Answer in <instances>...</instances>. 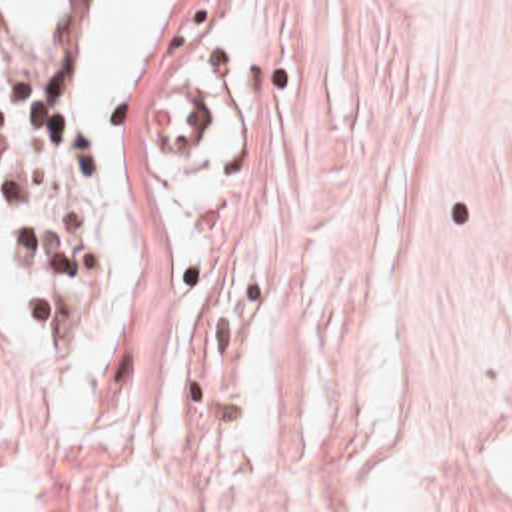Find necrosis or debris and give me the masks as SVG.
I'll return each instance as SVG.
<instances>
[{
    "mask_svg": "<svg viewBox=\"0 0 512 512\" xmlns=\"http://www.w3.org/2000/svg\"><path fill=\"white\" fill-rule=\"evenodd\" d=\"M76 0H0V166L38 270L40 312L94 282V180L70 118Z\"/></svg>",
    "mask_w": 512,
    "mask_h": 512,
    "instance_id": "necrosis-or-debris-1",
    "label": "necrosis or debris"
}]
</instances>
